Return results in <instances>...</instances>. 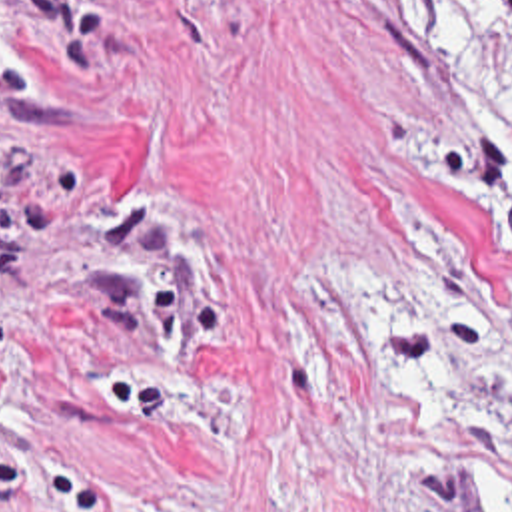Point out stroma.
<instances>
[{"label": "stroma", "mask_w": 512, "mask_h": 512, "mask_svg": "<svg viewBox=\"0 0 512 512\" xmlns=\"http://www.w3.org/2000/svg\"><path fill=\"white\" fill-rule=\"evenodd\" d=\"M406 0H0V512H512V255Z\"/></svg>", "instance_id": "stroma-1"}]
</instances>
